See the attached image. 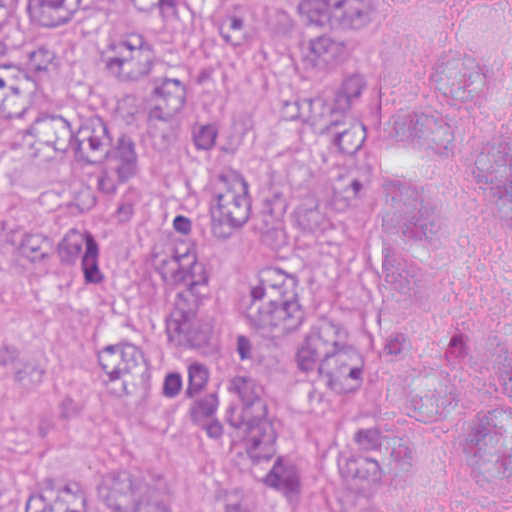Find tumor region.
<instances>
[{
	"label": "tumor region",
	"mask_w": 512,
	"mask_h": 512,
	"mask_svg": "<svg viewBox=\"0 0 512 512\" xmlns=\"http://www.w3.org/2000/svg\"><path fill=\"white\" fill-rule=\"evenodd\" d=\"M0 0V180L76 210L130 182L141 143L66 95L91 46L168 148L208 152L231 113L145 37L186 0ZM330 74L294 159L218 150L199 189L115 233L133 291L89 356L115 405L190 429L213 512H414L425 442L450 419L475 465L443 512L512 499V0H406L409 59L333 69L366 0H284ZM260 0H212L249 39ZM114 252L0 207V268L86 284ZM0 512H175L159 482L80 445L0 451Z\"/></svg>",
	"instance_id": "e687c5a6"
}]
</instances>
